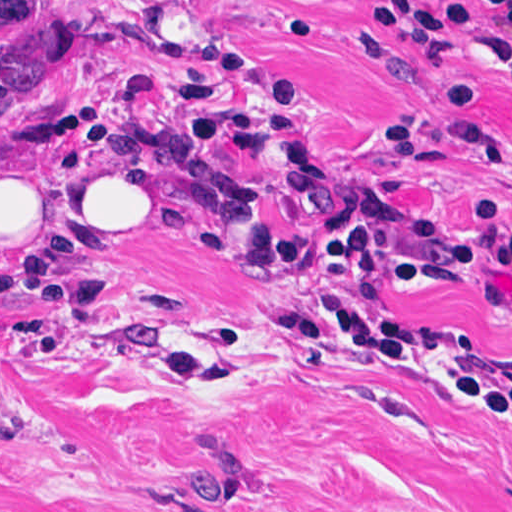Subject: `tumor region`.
Listing matches in <instances>:
<instances>
[{
  "label": "tumor region",
  "instance_id": "tumor-region-1",
  "mask_svg": "<svg viewBox=\"0 0 512 512\" xmlns=\"http://www.w3.org/2000/svg\"><path fill=\"white\" fill-rule=\"evenodd\" d=\"M180 487L196 503H231L244 494V458L216 426L203 423L185 450L178 469Z\"/></svg>",
  "mask_w": 512,
  "mask_h": 512
}]
</instances>
